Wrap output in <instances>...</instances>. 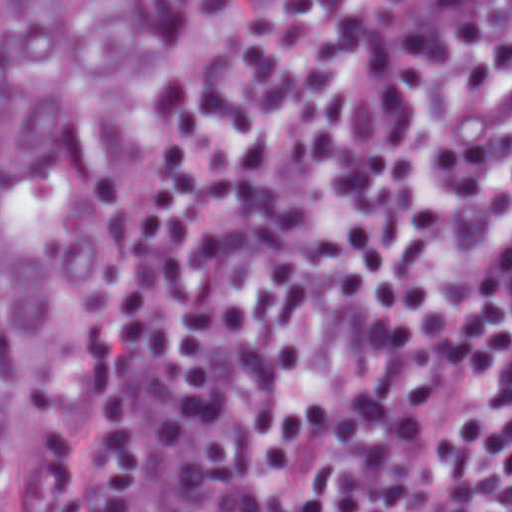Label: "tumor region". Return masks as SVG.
Segmentation results:
<instances>
[{
  "instance_id": "e687c5a6",
  "label": "tumor region",
  "mask_w": 512,
  "mask_h": 512,
  "mask_svg": "<svg viewBox=\"0 0 512 512\" xmlns=\"http://www.w3.org/2000/svg\"><path fill=\"white\" fill-rule=\"evenodd\" d=\"M247 1H1V512Z\"/></svg>"
}]
</instances>
